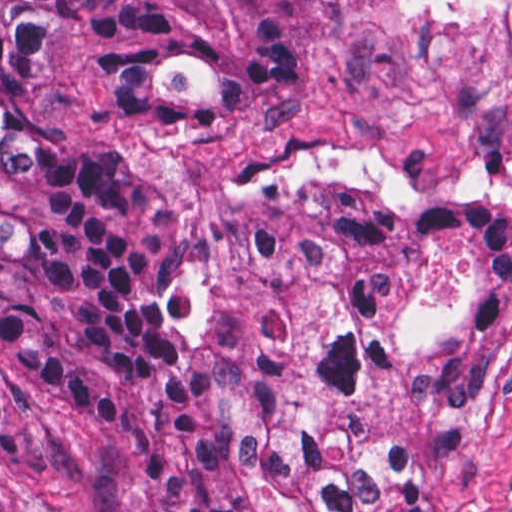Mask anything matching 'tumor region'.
<instances>
[{"mask_svg": "<svg viewBox=\"0 0 512 512\" xmlns=\"http://www.w3.org/2000/svg\"><path fill=\"white\" fill-rule=\"evenodd\" d=\"M353 3L0 0V368L108 434L141 512H449L432 480L504 350L512 209L319 185L195 225L48 122V61L69 47L115 125L314 86ZM446 236L474 247V305L372 437L335 417ZM0 512L46 511L0 484Z\"/></svg>", "mask_w": 512, "mask_h": 512, "instance_id": "tumor-region-1", "label": "tumor region"}]
</instances>
